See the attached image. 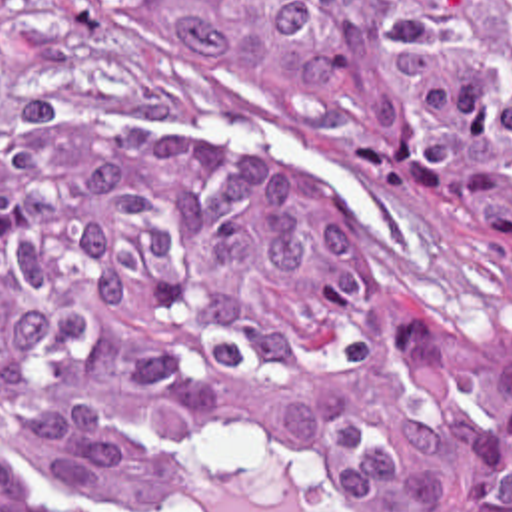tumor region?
Wrapping results in <instances>:
<instances>
[{
	"label": "tumor region",
	"instance_id": "obj_1",
	"mask_svg": "<svg viewBox=\"0 0 512 512\" xmlns=\"http://www.w3.org/2000/svg\"><path fill=\"white\" fill-rule=\"evenodd\" d=\"M149 92L271 100L355 168H441L512 236V0H0V418L121 512L207 446L351 512H512V356L405 292L335 194ZM0 512H85L0 452Z\"/></svg>",
	"mask_w": 512,
	"mask_h": 512
}]
</instances>
